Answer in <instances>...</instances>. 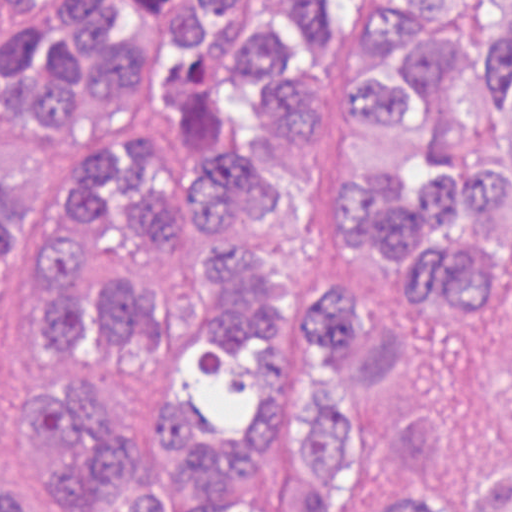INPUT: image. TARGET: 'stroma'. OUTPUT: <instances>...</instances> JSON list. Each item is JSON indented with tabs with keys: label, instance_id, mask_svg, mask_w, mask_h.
Wrapping results in <instances>:
<instances>
[{
	"label": "stroma",
	"instance_id": "35a3bbf8",
	"mask_svg": "<svg viewBox=\"0 0 512 512\" xmlns=\"http://www.w3.org/2000/svg\"><path fill=\"white\" fill-rule=\"evenodd\" d=\"M353 1L323 3L327 14H338ZM50 2L0 6V32L47 16ZM174 2L134 0L122 11L113 33L140 45L137 82L108 92H86L74 85L77 116L61 131L0 101V166L27 175V251L0 335L2 390L29 376H63L130 395L193 325L209 322L203 303L209 287L208 240L194 249L192 276L174 289L173 335L157 356L133 357L103 334L90 351L59 355L42 349L29 334V314L51 292L38 277V249L51 236H66L63 187L79 182V164L87 151L123 160L145 142L161 139L164 155L152 171L176 190L182 223L176 237L142 244L119 216L100 213V231L84 237L76 254L82 297L97 294L118 272H134L141 289L158 294L169 283L172 266L198 244V218L184 186L194 169L181 117L175 104L160 101L157 87L169 58L163 26ZM228 143L245 155L268 201L262 215L234 203L222 211L213 226L219 242L249 257L253 275L286 301L342 286L348 320L340 344L375 425L377 465L427 477L467 509L488 486L512 472V272L462 376L409 451L389 376V346L414 329L405 305L332 237L327 193L309 140L298 139L284 109L272 101L241 115ZM267 322L293 323L283 313ZM0 471L31 512H66L26 443L16 439L0 446Z\"/></svg>",
	"mask_w": 512,
	"mask_h": 512
}]
</instances>
